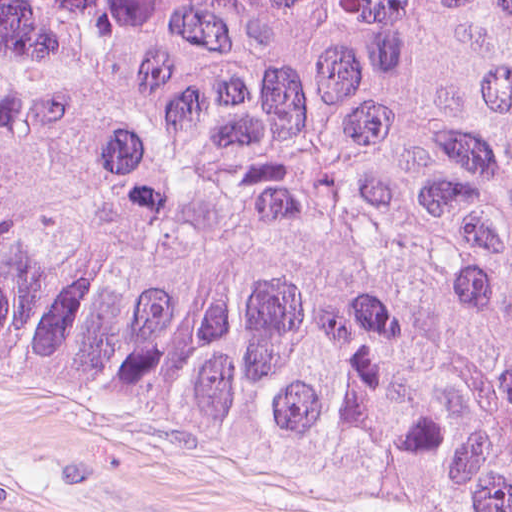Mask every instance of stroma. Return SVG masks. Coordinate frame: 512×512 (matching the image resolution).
<instances>
[{
    "instance_id": "obj_1",
    "label": "stroma",
    "mask_w": 512,
    "mask_h": 512,
    "mask_svg": "<svg viewBox=\"0 0 512 512\" xmlns=\"http://www.w3.org/2000/svg\"><path fill=\"white\" fill-rule=\"evenodd\" d=\"M0 512H450L94 376L0 363Z\"/></svg>"
}]
</instances>
